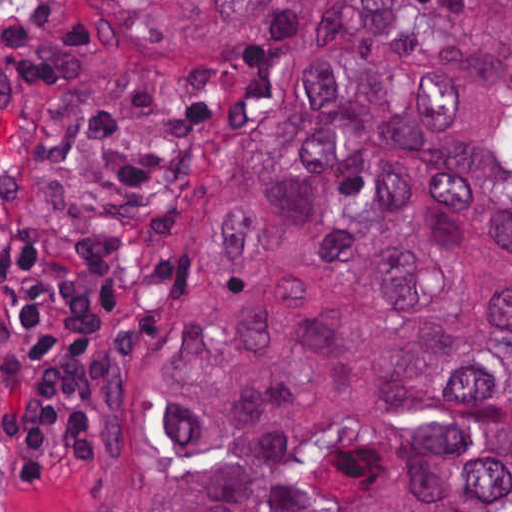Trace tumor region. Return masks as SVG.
Segmentation results:
<instances>
[{
    "mask_svg": "<svg viewBox=\"0 0 512 512\" xmlns=\"http://www.w3.org/2000/svg\"><path fill=\"white\" fill-rule=\"evenodd\" d=\"M287 2L63 157L201 227L116 512H512V1Z\"/></svg>",
    "mask_w": 512,
    "mask_h": 512,
    "instance_id": "e687c5a6",
    "label": "tumor region"
}]
</instances>
